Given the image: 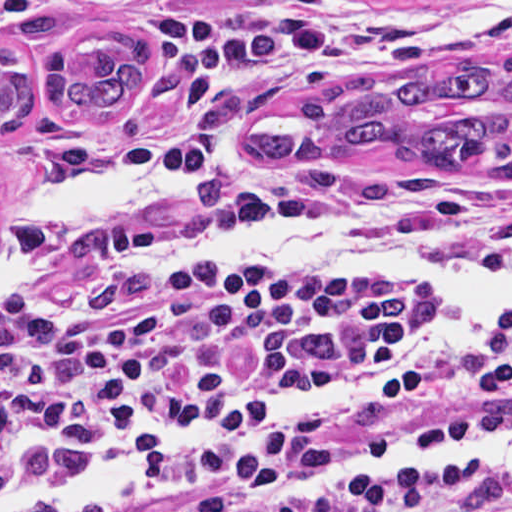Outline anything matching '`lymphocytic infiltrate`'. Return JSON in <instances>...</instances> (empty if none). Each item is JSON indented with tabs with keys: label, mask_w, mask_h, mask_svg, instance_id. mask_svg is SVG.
<instances>
[{
	"label": "lymphocytic infiltrate",
	"mask_w": 512,
	"mask_h": 512,
	"mask_svg": "<svg viewBox=\"0 0 512 512\" xmlns=\"http://www.w3.org/2000/svg\"><path fill=\"white\" fill-rule=\"evenodd\" d=\"M433 307L411 290L214 285L164 258L84 252L0 289V392L30 448L86 458L175 426L231 429L286 383L390 362ZM440 369L451 399L426 436L292 430L68 512H512L511 483L469 470H378L287 495L386 451L500 443L512 328Z\"/></svg>",
	"instance_id": "obj_1"
}]
</instances>
